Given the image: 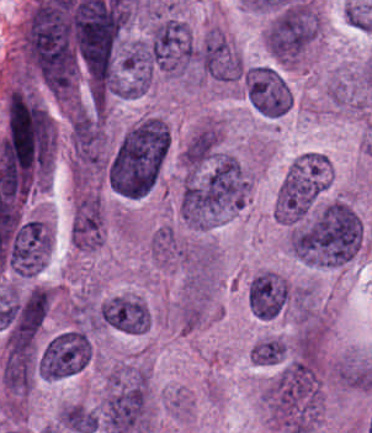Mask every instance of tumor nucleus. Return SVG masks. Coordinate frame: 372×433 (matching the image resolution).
<instances>
[{
	"label": "tumor nucleus",
	"mask_w": 372,
	"mask_h": 433,
	"mask_svg": "<svg viewBox=\"0 0 372 433\" xmlns=\"http://www.w3.org/2000/svg\"><path fill=\"white\" fill-rule=\"evenodd\" d=\"M285 357V341L269 336L256 340L250 346L249 361L256 364H276Z\"/></svg>",
	"instance_id": "12"
},
{
	"label": "tumor nucleus",
	"mask_w": 372,
	"mask_h": 433,
	"mask_svg": "<svg viewBox=\"0 0 372 433\" xmlns=\"http://www.w3.org/2000/svg\"><path fill=\"white\" fill-rule=\"evenodd\" d=\"M317 31V13L304 0H291L266 26V49L284 62H291L312 41Z\"/></svg>",
	"instance_id": "4"
},
{
	"label": "tumor nucleus",
	"mask_w": 372,
	"mask_h": 433,
	"mask_svg": "<svg viewBox=\"0 0 372 433\" xmlns=\"http://www.w3.org/2000/svg\"><path fill=\"white\" fill-rule=\"evenodd\" d=\"M360 236L357 213L344 201L332 200L298 221L287 232V244L300 260L334 266L353 256Z\"/></svg>",
	"instance_id": "2"
},
{
	"label": "tumor nucleus",
	"mask_w": 372,
	"mask_h": 433,
	"mask_svg": "<svg viewBox=\"0 0 372 433\" xmlns=\"http://www.w3.org/2000/svg\"><path fill=\"white\" fill-rule=\"evenodd\" d=\"M202 72L221 81L240 78L241 60L222 31L208 30L196 46Z\"/></svg>",
	"instance_id": "8"
},
{
	"label": "tumor nucleus",
	"mask_w": 372,
	"mask_h": 433,
	"mask_svg": "<svg viewBox=\"0 0 372 433\" xmlns=\"http://www.w3.org/2000/svg\"><path fill=\"white\" fill-rule=\"evenodd\" d=\"M149 422L148 386L143 368L113 370L107 377L95 423L113 433H145Z\"/></svg>",
	"instance_id": "3"
},
{
	"label": "tumor nucleus",
	"mask_w": 372,
	"mask_h": 433,
	"mask_svg": "<svg viewBox=\"0 0 372 433\" xmlns=\"http://www.w3.org/2000/svg\"><path fill=\"white\" fill-rule=\"evenodd\" d=\"M194 52L195 44L186 22L165 17L152 25L143 57L150 68L181 74L187 70Z\"/></svg>",
	"instance_id": "5"
},
{
	"label": "tumor nucleus",
	"mask_w": 372,
	"mask_h": 433,
	"mask_svg": "<svg viewBox=\"0 0 372 433\" xmlns=\"http://www.w3.org/2000/svg\"><path fill=\"white\" fill-rule=\"evenodd\" d=\"M168 149L165 122L141 117L116 140L106 161V183L119 195L140 196L154 185Z\"/></svg>",
	"instance_id": "1"
},
{
	"label": "tumor nucleus",
	"mask_w": 372,
	"mask_h": 433,
	"mask_svg": "<svg viewBox=\"0 0 372 433\" xmlns=\"http://www.w3.org/2000/svg\"><path fill=\"white\" fill-rule=\"evenodd\" d=\"M220 131L211 122H203L186 140L180 159L186 168H199L216 151Z\"/></svg>",
	"instance_id": "11"
},
{
	"label": "tumor nucleus",
	"mask_w": 372,
	"mask_h": 433,
	"mask_svg": "<svg viewBox=\"0 0 372 433\" xmlns=\"http://www.w3.org/2000/svg\"><path fill=\"white\" fill-rule=\"evenodd\" d=\"M243 87L249 104L260 115L276 117L287 111L288 86L277 69L264 64L247 68Z\"/></svg>",
	"instance_id": "7"
},
{
	"label": "tumor nucleus",
	"mask_w": 372,
	"mask_h": 433,
	"mask_svg": "<svg viewBox=\"0 0 372 433\" xmlns=\"http://www.w3.org/2000/svg\"><path fill=\"white\" fill-rule=\"evenodd\" d=\"M103 215L101 200L91 191H84L78 198L71 222L70 240L81 250H92L102 241Z\"/></svg>",
	"instance_id": "9"
},
{
	"label": "tumor nucleus",
	"mask_w": 372,
	"mask_h": 433,
	"mask_svg": "<svg viewBox=\"0 0 372 433\" xmlns=\"http://www.w3.org/2000/svg\"><path fill=\"white\" fill-rule=\"evenodd\" d=\"M147 315L145 304L129 296H110L96 306L101 324L128 333L145 331Z\"/></svg>",
	"instance_id": "10"
},
{
	"label": "tumor nucleus",
	"mask_w": 372,
	"mask_h": 433,
	"mask_svg": "<svg viewBox=\"0 0 372 433\" xmlns=\"http://www.w3.org/2000/svg\"><path fill=\"white\" fill-rule=\"evenodd\" d=\"M44 378H61L82 369L91 348L87 334L80 328H66L49 337L41 348Z\"/></svg>",
	"instance_id": "6"
}]
</instances>
